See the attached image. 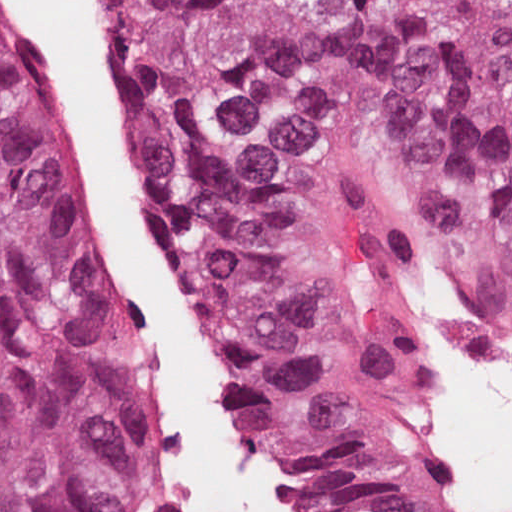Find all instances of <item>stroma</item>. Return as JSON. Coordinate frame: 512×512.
Masks as SVG:
<instances>
[{
  "instance_id": "1",
  "label": "stroma",
  "mask_w": 512,
  "mask_h": 512,
  "mask_svg": "<svg viewBox=\"0 0 512 512\" xmlns=\"http://www.w3.org/2000/svg\"><path fill=\"white\" fill-rule=\"evenodd\" d=\"M89 2L93 7L97 26L108 46L119 104V57L114 41V24L105 9L103 0H89ZM120 116L126 149L147 198L154 225L151 200L143 171L124 129L121 111ZM395 225L398 243L410 278V319L407 327V348L408 353H410L416 329L429 307H435L431 283L420 266V242L435 246L432 244L426 231L415 219L401 213ZM500 298L512 306V298ZM141 339L145 348L142 327ZM413 413L415 420V460L430 502L436 512H480L478 509L471 508L468 502L461 497L444 467L433 439L421 422L415 406H413ZM236 430L250 464L258 475L287 499L298 505L304 512H307L306 489L291 476L280 458L261 450L242 435L237 428ZM161 447L162 442L158 421V441L153 465L141 489L135 512H149L150 510Z\"/></svg>"
}]
</instances>
